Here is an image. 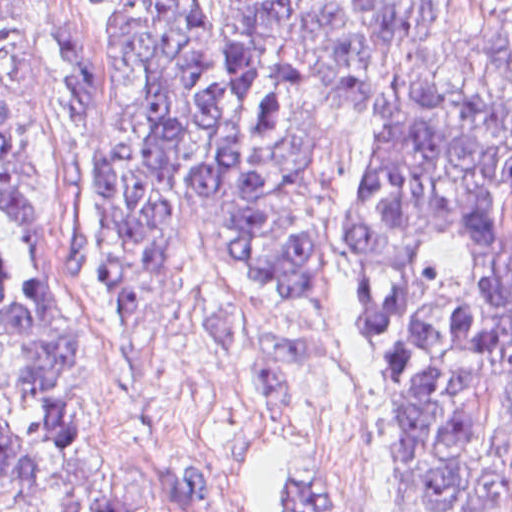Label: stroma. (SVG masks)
<instances>
[{
  "mask_svg": "<svg viewBox=\"0 0 512 512\" xmlns=\"http://www.w3.org/2000/svg\"><path fill=\"white\" fill-rule=\"evenodd\" d=\"M114 32L104 0H33L41 155L66 214L77 376L76 429L49 451L38 512H72L100 475L128 462L210 474L226 512H376L395 474V417L350 263V206L375 125L355 122L326 199L322 291L237 292L200 246L181 283L107 316L103 118ZM0 426L29 434L1 390Z\"/></svg>",
  "mask_w": 512,
  "mask_h": 512,
  "instance_id": "35a3bbf8",
  "label": "stroma"
}]
</instances>
